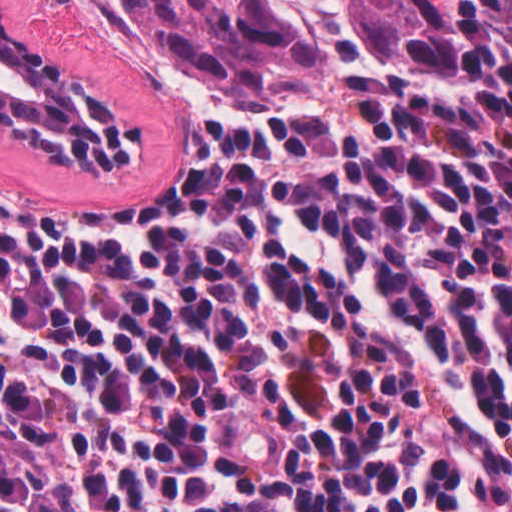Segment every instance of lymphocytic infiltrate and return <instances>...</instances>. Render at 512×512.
<instances>
[{"label":"lymphocytic infiltrate","mask_w":512,"mask_h":512,"mask_svg":"<svg viewBox=\"0 0 512 512\" xmlns=\"http://www.w3.org/2000/svg\"><path fill=\"white\" fill-rule=\"evenodd\" d=\"M0 512H512V0L147 209L0 187Z\"/></svg>","instance_id":"obj_1"}]
</instances>
